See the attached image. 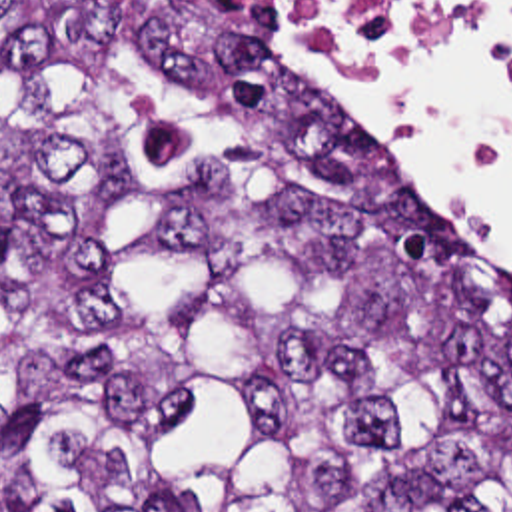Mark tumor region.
I'll return each mask as SVG.
<instances>
[{"label":"tumor region","instance_id":"tumor-region-1","mask_svg":"<svg viewBox=\"0 0 512 512\" xmlns=\"http://www.w3.org/2000/svg\"><path fill=\"white\" fill-rule=\"evenodd\" d=\"M208 0H0V512H512V278Z\"/></svg>","mask_w":512,"mask_h":512}]
</instances>
